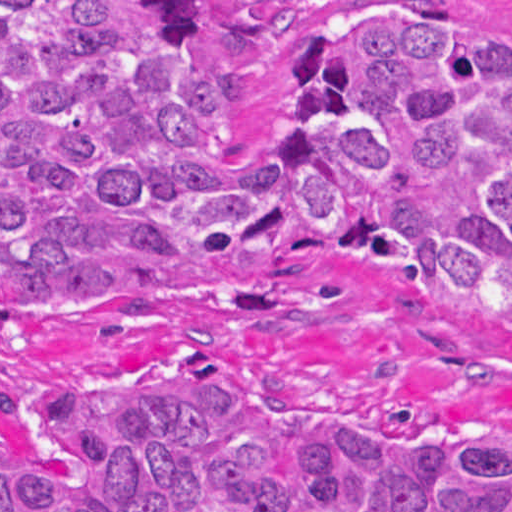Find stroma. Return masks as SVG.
I'll use <instances>...</instances> for the list:
<instances>
[{"instance_id":"1","label":"stroma","mask_w":512,"mask_h":512,"mask_svg":"<svg viewBox=\"0 0 512 512\" xmlns=\"http://www.w3.org/2000/svg\"><path fill=\"white\" fill-rule=\"evenodd\" d=\"M1 1H288L278 52L255 68L231 135L263 125L286 41L329 1H460L512 35V0H0V512L1 453L38 468L70 457L12 429L4 399L46 383L125 389L168 356L201 359L226 392L297 428L358 419L416 448L512 434V326L426 297L371 259L249 263L1 310Z\"/></svg>"}]
</instances>
